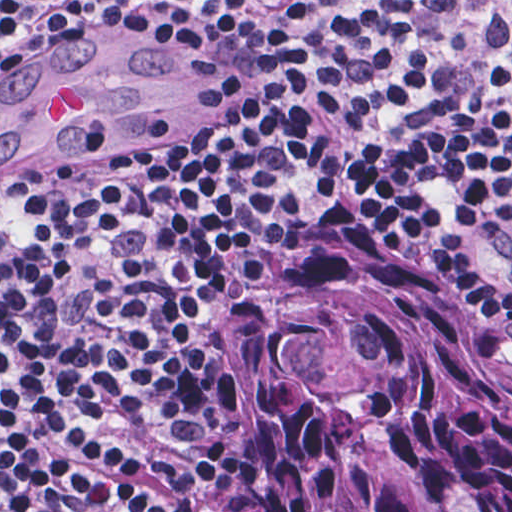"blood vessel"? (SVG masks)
Segmentation results:
<instances>
[{"label": "blood vessel", "mask_w": 512, "mask_h": 512, "mask_svg": "<svg viewBox=\"0 0 512 512\" xmlns=\"http://www.w3.org/2000/svg\"><path fill=\"white\" fill-rule=\"evenodd\" d=\"M66 36L0 81V184H42L144 142L177 32L137 18Z\"/></svg>", "instance_id": "blood-vessel-1"}]
</instances>
